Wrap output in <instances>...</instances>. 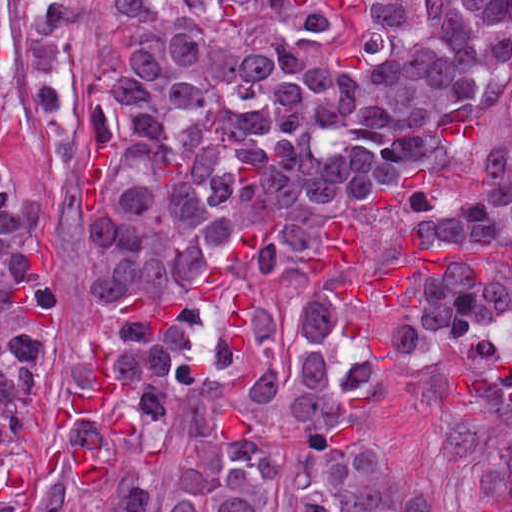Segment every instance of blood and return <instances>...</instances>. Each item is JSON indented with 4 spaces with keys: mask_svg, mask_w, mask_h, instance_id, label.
Wrapping results in <instances>:
<instances>
[{
    "mask_svg": "<svg viewBox=\"0 0 512 512\" xmlns=\"http://www.w3.org/2000/svg\"><path fill=\"white\" fill-rule=\"evenodd\" d=\"M321 7L339 11L346 0H315ZM302 270L316 278H334L359 272L349 280H335L332 294L361 307L383 298L385 307H409L419 294L413 284L420 272H437L450 263L473 264L479 278L493 267L494 253H481L457 244H427L407 223V241L401 254L375 261L368 237L349 217H331L318 223V239L305 242L299 254ZM119 386L108 366V349L93 345L86 379L75 381L56 405L50 419L62 430L69 419L100 417L116 439H134L135 426L114 414Z\"/></svg>",
    "mask_w": 512,
    "mask_h": 512,
    "instance_id": "obj_1",
    "label": "blood"
}]
</instances>
